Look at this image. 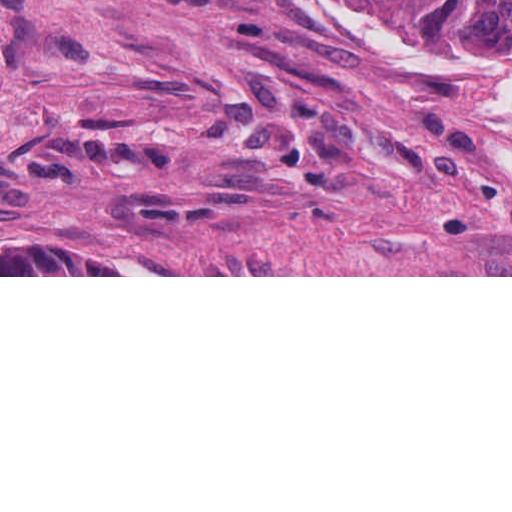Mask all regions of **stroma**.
<instances>
[{
	"label": "stroma",
	"mask_w": 512,
	"mask_h": 512,
	"mask_svg": "<svg viewBox=\"0 0 512 512\" xmlns=\"http://www.w3.org/2000/svg\"><path fill=\"white\" fill-rule=\"evenodd\" d=\"M141 262L1 275V248ZM0 277H512V44L375 0H0Z\"/></svg>",
	"instance_id": "1"
}]
</instances>
